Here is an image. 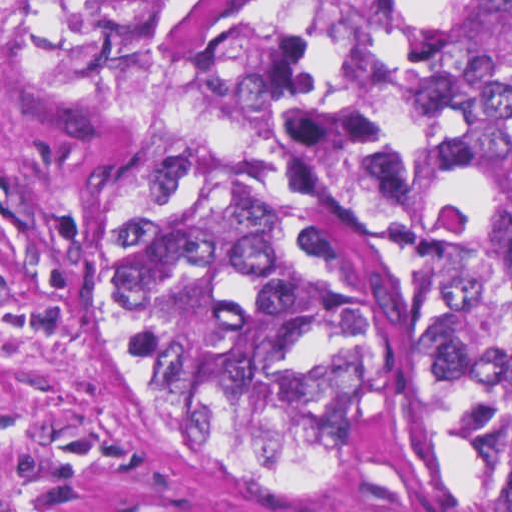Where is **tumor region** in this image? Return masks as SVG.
Instances as JSON below:
<instances>
[{
    "label": "tumor region",
    "instance_id": "1",
    "mask_svg": "<svg viewBox=\"0 0 512 512\" xmlns=\"http://www.w3.org/2000/svg\"><path fill=\"white\" fill-rule=\"evenodd\" d=\"M200 1L0 0L5 65L131 161L120 367L271 490L512 489V0H332L282 192L202 89Z\"/></svg>",
    "mask_w": 512,
    "mask_h": 512
}]
</instances>
